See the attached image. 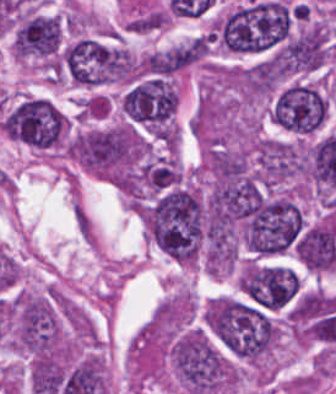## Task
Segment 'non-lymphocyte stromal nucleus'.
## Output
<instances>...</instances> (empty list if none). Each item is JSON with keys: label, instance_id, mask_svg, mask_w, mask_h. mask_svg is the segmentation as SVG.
<instances>
[{"label": "non-lymphocyte stromal nucleus", "instance_id": "obj_1", "mask_svg": "<svg viewBox=\"0 0 336 394\" xmlns=\"http://www.w3.org/2000/svg\"><path fill=\"white\" fill-rule=\"evenodd\" d=\"M72 217L74 226L86 246L94 247L96 234L93 222L80 201L74 199L72 204Z\"/></svg>", "mask_w": 336, "mask_h": 394}]
</instances>
